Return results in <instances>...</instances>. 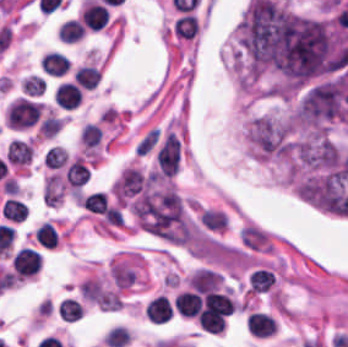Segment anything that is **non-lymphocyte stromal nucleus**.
Returning <instances> with one entry per match:
<instances>
[{
	"label": "non-lymphocyte stromal nucleus",
	"instance_id": "dd21d789",
	"mask_svg": "<svg viewBox=\"0 0 348 347\" xmlns=\"http://www.w3.org/2000/svg\"><path fill=\"white\" fill-rule=\"evenodd\" d=\"M181 146L171 131L167 133L156 157L157 175L172 177L177 171Z\"/></svg>",
	"mask_w": 348,
	"mask_h": 347
},
{
	"label": "non-lymphocyte stromal nucleus",
	"instance_id": "a72fc3eb",
	"mask_svg": "<svg viewBox=\"0 0 348 347\" xmlns=\"http://www.w3.org/2000/svg\"><path fill=\"white\" fill-rule=\"evenodd\" d=\"M64 193V181L58 174H51L44 182L42 199L46 206H56Z\"/></svg>",
	"mask_w": 348,
	"mask_h": 347
},
{
	"label": "non-lymphocyte stromal nucleus",
	"instance_id": "3746e769",
	"mask_svg": "<svg viewBox=\"0 0 348 347\" xmlns=\"http://www.w3.org/2000/svg\"><path fill=\"white\" fill-rule=\"evenodd\" d=\"M158 139V133L154 128L149 130L134 146L135 154H143L148 151Z\"/></svg>",
	"mask_w": 348,
	"mask_h": 347
}]
</instances>
